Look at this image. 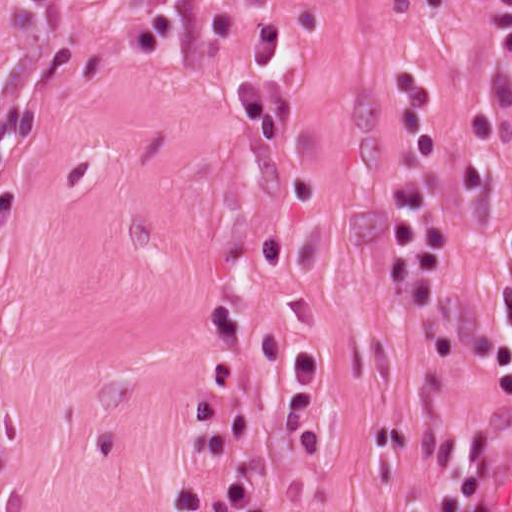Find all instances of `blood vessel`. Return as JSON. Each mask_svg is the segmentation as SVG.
Listing matches in <instances>:
<instances>
[{"mask_svg":"<svg viewBox=\"0 0 512 512\" xmlns=\"http://www.w3.org/2000/svg\"><path fill=\"white\" fill-rule=\"evenodd\" d=\"M487 512H512V430L489 488Z\"/></svg>","mask_w":512,"mask_h":512,"instance_id":"obj_1","label":"blood vessel"}]
</instances>
